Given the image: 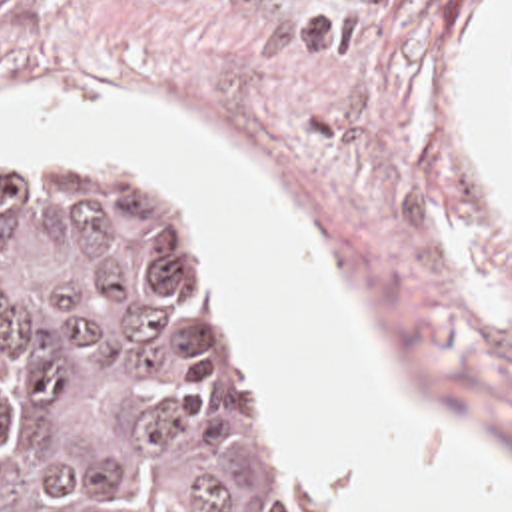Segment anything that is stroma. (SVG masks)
Wrapping results in <instances>:
<instances>
[{"label": "stroma", "mask_w": 512, "mask_h": 512, "mask_svg": "<svg viewBox=\"0 0 512 512\" xmlns=\"http://www.w3.org/2000/svg\"><path fill=\"white\" fill-rule=\"evenodd\" d=\"M480 0H0V106L104 92L202 130L324 246L328 270L406 404L476 442L512 482V218L458 106ZM500 134L512 164V68ZM3 154L114 164L156 196L210 280L220 344L256 432L304 512L300 480L210 278V250L142 170L0 136Z\"/></svg>", "instance_id": "stroma-1"}]
</instances>
